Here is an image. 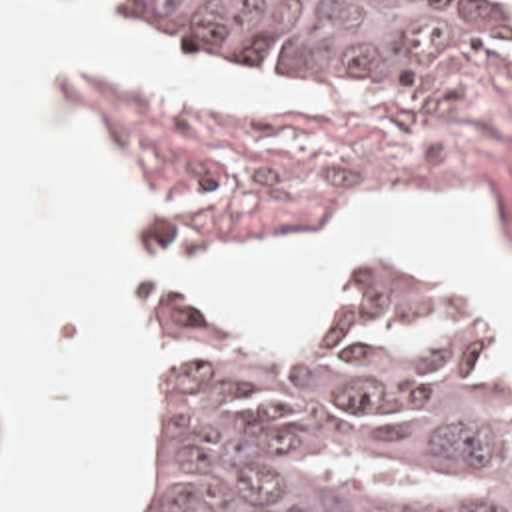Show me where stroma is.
<instances>
[{
  "label": "stroma",
  "instance_id": "obj_1",
  "mask_svg": "<svg viewBox=\"0 0 512 512\" xmlns=\"http://www.w3.org/2000/svg\"><path fill=\"white\" fill-rule=\"evenodd\" d=\"M114 14L158 26L236 70L316 90L320 102L274 108L160 100L116 78L64 74L72 110L134 164L150 246L134 288V320L150 346L152 404L138 472L110 512L144 499L154 476V416L166 390L168 340L184 322H212L284 350L318 346L336 328L344 302L390 268L488 330L498 382L512 398L510 348L466 290L434 268L362 260L322 332L302 340L262 338L170 284V252L210 258L276 234L330 228L352 202L376 196L486 194L492 220L512 242V48L448 74H322L208 30L150 20L136 0H116Z\"/></svg>",
  "mask_w": 512,
  "mask_h": 512
}]
</instances>
